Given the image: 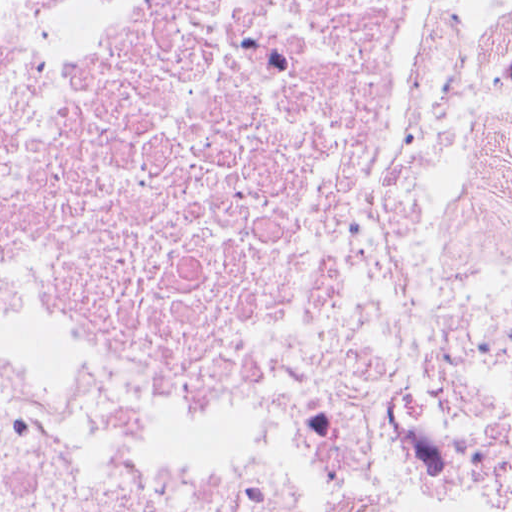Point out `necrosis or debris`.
<instances>
[{"mask_svg": "<svg viewBox=\"0 0 512 512\" xmlns=\"http://www.w3.org/2000/svg\"><path fill=\"white\" fill-rule=\"evenodd\" d=\"M411 0H0V323L87 353L320 358L369 308ZM390 393L0 377L1 512H384L412 436L512 446V0L416 205ZM444 512H512V476Z\"/></svg>", "mask_w": 512, "mask_h": 512, "instance_id": "obj_1", "label": "necrosis or debris"}]
</instances>
